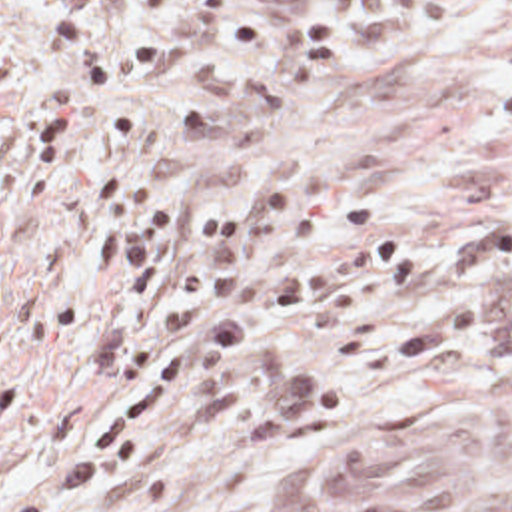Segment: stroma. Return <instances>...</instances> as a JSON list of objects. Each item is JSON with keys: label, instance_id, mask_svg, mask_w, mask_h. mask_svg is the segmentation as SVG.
Instances as JSON below:
<instances>
[{"label": "stroma", "instance_id": "35a3bbf8", "mask_svg": "<svg viewBox=\"0 0 512 512\" xmlns=\"http://www.w3.org/2000/svg\"><path fill=\"white\" fill-rule=\"evenodd\" d=\"M77 0H15L0 19V510L73 452L107 402L89 339L117 281L87 251L99 207L77 173L39 197L11 183V147L59 91L79 97L81 147L187 211H245L267 183L291 197L361 203L367 225L281 263L388 235L422 257V283L369 323L317 331L291 315L257 343L327 370L333 418L257 446L219 394L181 398L145 450L81 512H303L299 476L339 442L404 418L450 414L480 432L470 494L428 512H512V404L476 390L468 355L434 369H365L369 345L406 333L444 293V273L484 221L512 213V0H237L229 31L195 59L119 89H67L41 23ZM139 0L105 27L157 33ZM281 237L251 259L267 267Z\"/></svg>", "mask_w": 512, "mask_h": 512}]
</instances>
